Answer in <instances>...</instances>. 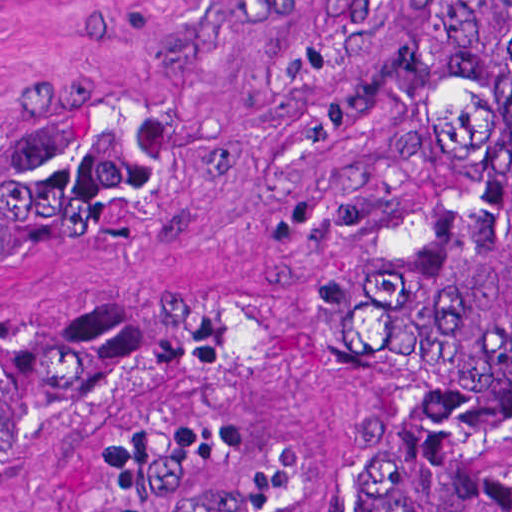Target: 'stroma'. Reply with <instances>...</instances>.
I'll use <instances>...</instances> for the list:
<instances>
[{"label":"stroma","mask_w":512,"mask_h":512,"mask_svg":"<svg viewBox=\"0 0 512 512\" xmlns=\"http://www.w3.org/2000/svg\"><path fill=\"white\" fill-rule=\"evenodd\" d=\"M447 0H0V107L69 100L136 159L114 217L0 323L162 355L0 431V512H146L198 431L261 447L269 512H360L368 306ZM512 512V384L469 461Z\"/></svg>","instance_id":"35a3bbf8"}]
</instances>
